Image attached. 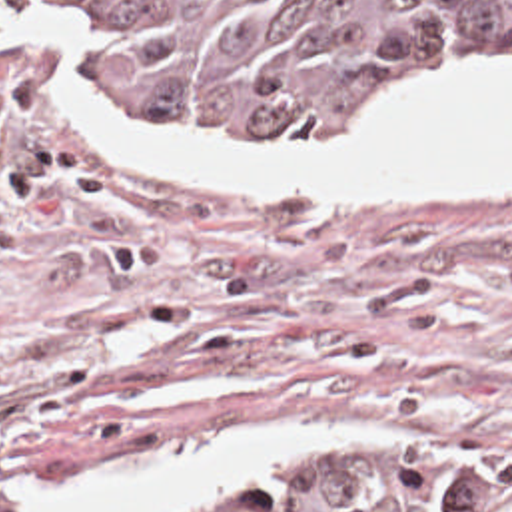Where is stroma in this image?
<instances>
[{
    "mask_svg": "<svg viewBox=\"0 0 512 512\" xmlns=\"http://www.w3.org/2000/svg\"><path fill=\"white\" fill-rule=\"evenodd\" d=\"M494 73L512 61L390 75L330 139H225L153 105L41 115L1 139V460L57 476L235 431L374 425L336 446L438 454L512 490V195L179 197L77 145L85 121L159 117L215 145L356 149L396 81ZM0 512H23L1 468Z\"/></svg>",
    "mask_w": 512,
    "mask_h": 512,
    "instance_id": "1",
    "label": "stroma"
}]
</instances>
